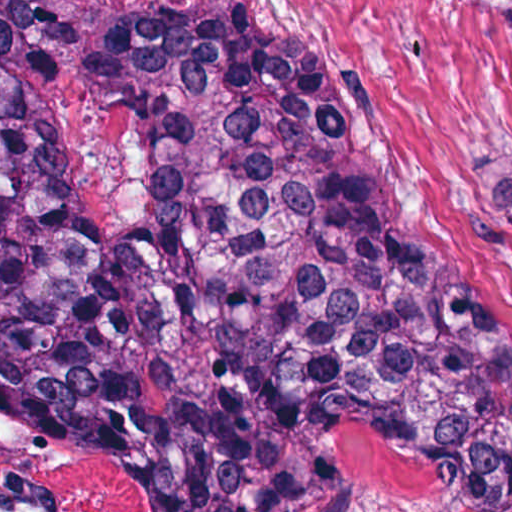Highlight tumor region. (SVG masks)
Returning a JSON list of instances; mask_svg holds the SVG:
<instances>
[{
  "instance_id": "obj_1",
  "label": "tumor region",
  "mask_w": 512,
  "mask_h": 512,
  "mask_svg": "<svg viewBox=\"0 0 512 512\" xmlns=\"http://www.w3.org/2000/svg\"><path fill=\"white\" fill-rule=\"evenodd\" d=\"M0 386L153 512H356L338 418L442 512H512V352L394 218L333 71L67 1H0Z\"/></svg>"
}]
</instances>
